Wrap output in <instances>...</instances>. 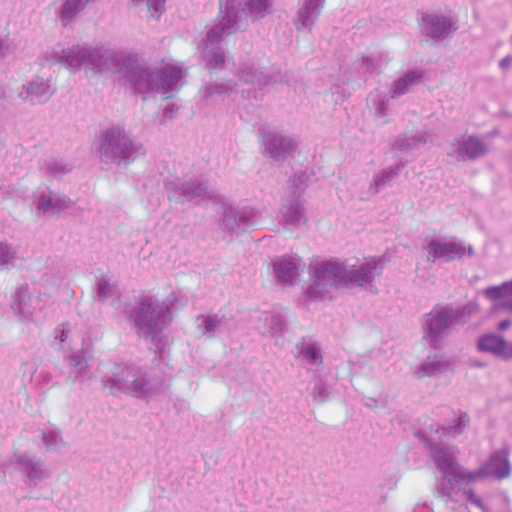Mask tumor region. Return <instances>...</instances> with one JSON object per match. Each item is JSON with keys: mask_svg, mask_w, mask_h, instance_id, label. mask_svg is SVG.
I'll use <instances>...</instances> for the list:
<instances>
[{"mask_svg": "<svg viewBox=\"0 0 512 512\" xmlns=\"http://www.w3.org/2000/svg\"><path fill=\"white\" fill-rule=\"evenodd\" d=\"M512 49V0H465ZM440 297L413 349L442 384L466 367L512 364V251L478 229L431 220L419 235ZM380 512H512V438L484 409L445 407L407 419Z\"/></svg>", "mask_w": 512, "mask_h": 512, "instance_id": "e687c5a6", "label": "tumor region"}]
</instances>
